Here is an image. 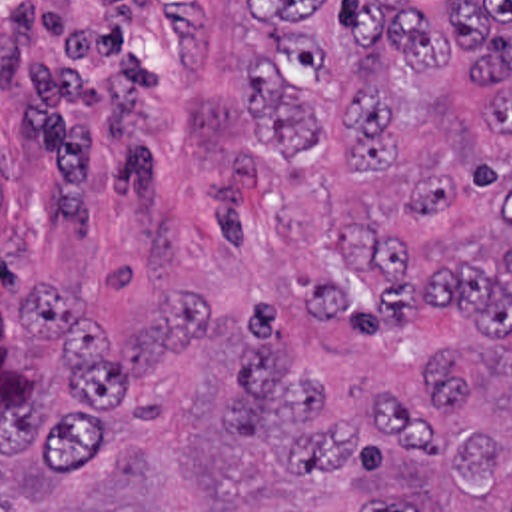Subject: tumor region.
<instances>
[{
  "instance_id": "e687c5a6",
  "label": "tumor region",
  "mask_w": 512,
  "mask_h": 512,
  "mask_svg": "<svg viewBox=\"0 0 512 512\" xmlns=\"http://www.w3.org/2000/svg\"><path fill=\"white\" fill-rule=\"evenodd\" d=\"M241 13L261 157L206 207L285 298L0 308V512H512V0Z\"/></svg>"
}]
</instances>
